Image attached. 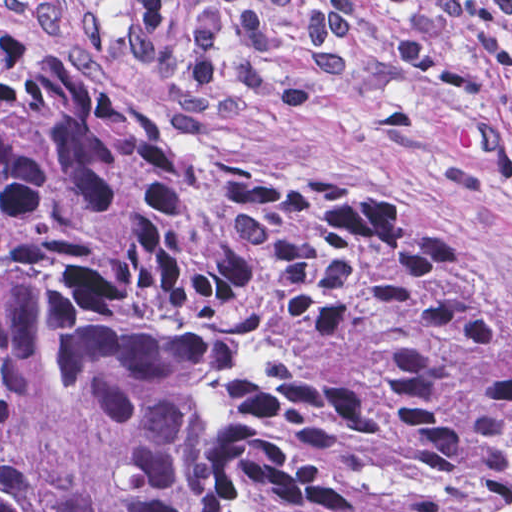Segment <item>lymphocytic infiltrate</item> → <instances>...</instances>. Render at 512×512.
Returning a JSON list of instances; mask_svg holds the SVG:
<instances>
[{"instance_id":"obj_1","label":"lymphocytic infiltrate","mask_w":512,"mask_h":512,"mask_svg":"<svg viewBox=\"0 0 512 512\" xmlns=\"http://www.w3.org/2000/svg\"><path fill=\"white\" fill-rule=\"evenodd\" d=\"M32 0V26H76L84 46H120L132 65L162 81L173 139L195 140L245 101L299 104L303 79L279 62L275 23L311 31V57L323 73L357 62L369 10L395 16L393 59L406 71L451 31L488 71L512 61V0Z\"/></svg>"}]
</instances>
